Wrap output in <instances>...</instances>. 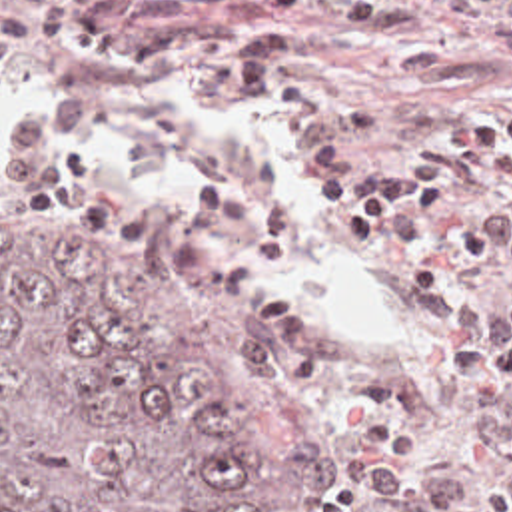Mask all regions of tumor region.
<instances>
[{"mask_svg": "<svg viewBox=\"0 0 512 512\" xmlns=\"http://www.w3.org/2000/svg\"><path fill=\"white\" fill-rule=\"evenodd\" d=\"M0 512H325V473L166 254L0 238Z\"/></svg>", "mask_w": 512, "mask_h": 512, "instance_id": "tumor-region-1", "label": "tumor region"}]
</instances>
